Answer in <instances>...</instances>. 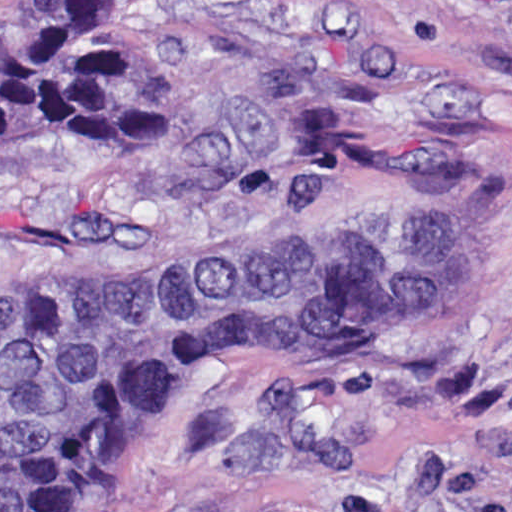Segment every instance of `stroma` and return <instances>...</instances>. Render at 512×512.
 Masks as SVG:
<instances>
[{"mask_svg":"<svg viewBox=\"0 0 512 512\" xmlns=\"http://www.w3.org/2000/svg\"><path fill=\"white\" fill-rule=\"evenodd\" d=\"M168 140L0 148V285L279 236L425 245L373 321L158 388L26 512H512V0H110Z\"/></svg>","mask_w":512,"mask_h":512,"instance_id":"stroma-1","label":"stroma"}]
</instances>
